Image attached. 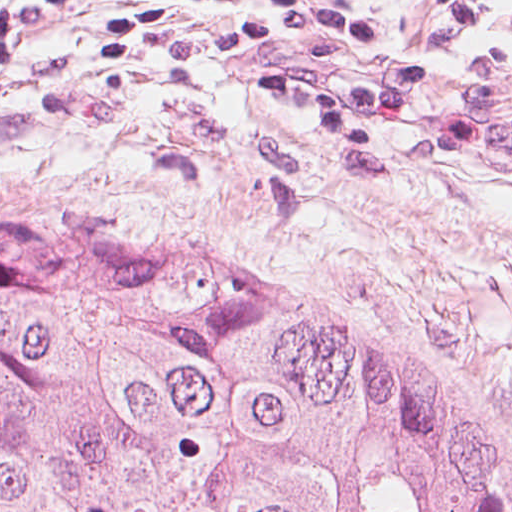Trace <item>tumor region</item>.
<instances>
[{
    "mask_svg": "<svg viewBox=\"0 0 512 512\" xmlns=\"http://www.w3.org/2000/svg\"><path fill=\"white\" fill-rule=\"evenodd\" d=\"M0 512H512L454 385L204 244L0 206Z\"/></svg>",
    "mask_w": 512,
    "mask_h": 512,
    "instance_id": "obj_1",
    "label": "tumor region"
}]
</instances>
